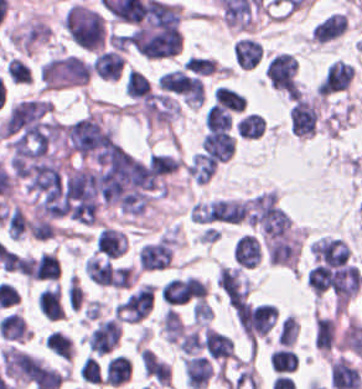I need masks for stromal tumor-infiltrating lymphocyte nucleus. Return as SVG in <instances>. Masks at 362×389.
<instances>
[{
	"label": "stromal tumor-infiltrating lymphocyte nucleus",
	"mask_w": 362,
	"mask_h": 389,
	"mask_svg": "<svg viewBox=\"0 0 362 389\" xmlns=\"http://www.w3.org/2000/svg\"><path fill=\"white\" fill-rule=\"evenodd\" d=\"M218 160L203 151H196L185 165V173L196 183L205 184L216 170Z\"/></svg>",
	"instance_id": "20"
},
{
	"label": "stromal tumor-infiltrating lymphocyte nucleus",
	"mask_w": 362,
	"mask_h": 389,
	"mask_svg": "<svg viewBox=\"0 0 362 389\" xmlns=\"http://www.w3.org/2000/svg\"><path fill=\"white\" fill-rule=\"evenodd\" d=\"M153 302V286L148 282L140 284L117 303V319L137 323L148 315Z\"/></svg>",
	"instance_id": "7"
},
{
	"label": "stromal tumor-infiltrating lymphocyte nucleus",
	"mask_w": 362,
	"mask_h": 389,
	"mask_svg": "<svg viewBox=\"0 0 362 389\" xmlns=\"http://www.w3.org/2000/svg\"><path fill=\"white\" fill-rule=\"evenodd\" d=\"M129 372L130 360L122 354H114L108 359L103 376L106 382L119 385L126 381Z\"/></svg>",
	"instance_id": "27"
},
{
	"label": "stromal tumor-infiltrating lymphocyte nucleus",
	"mask_w": 362,
	"mask_h": 389,
	"mask_svg": "<svg viewBox=\"0 0 362 389\" xmlns=\"http://www.w3.org/2000/svg\"><path fill=\"white\" fill-rule=\"evenodd\" d=\"M268 263L294 266L300 253L298 237L271 240L266 245Z\"/></svg>",
	"instance_id": "16"
},
{
	"label": "stromal tumor-infiltrating lymphocyte nucleus",
	"mask_w": 362,
	"mask_h": 389,
	"mask_svg": "<svg viewBox=\"0 0 362 389\" xmlns=\"http://www.w3.org/2000/svg\"><path fill=\"white\" fill-rule=\"evenodd\" d=\"M92 65L75 55L57 56L42 63L39 76L45 87L83 85Z\"/></svg>",
	"instance_id": "2"
},
{
	"label": "stromal tumor-infiltrating lymphocyte nucleus",
	"mask_w": 362,
	"mask_h": 389,
	"mask_svg": "<svg viewBox=\"0 0 362 389\" xmlns=\"http://www.w3.org/2000/svg\"><path fill=\"white\" fill-rule=\"evenodd\" d=\"M160 325L164 340L168 342H175L184 331L175 310L169 306L161 316Z\"/></svg>",
	"instance_id": "35"
},
{
	"label": "stromal tumor-infiltrating lymphocyte nucleus",
	"mask_w": 362,
	"mask_h": 389,
	"mask_svg": "<svg viewBox=\"0 0 362 389\" xmlns=\"http://www.w3.org/2000/svg\"><path fill=\"white\" fill-rule=\"evenodd\" d=\"M174 232H166L140 247L136 263L140 272H160L171 265L175 249Z\"/></svg>",
	"instance_id": "3"
},
{
	"label": "stromal tumor-infiltrating lymphocyte nucleus",
	"mask_w": 362,
	"mask_h": 389,
	"mask_svg": "<svg viewBox=\"0 0 362 389\" xmlns=\"http://www.w3.org/2000/svg\"><path fill=\"white\" fill-rule=\"evenodd\" d=\"M330 267L322 264L315 265L305 277V284L314 295L321 296L329 289Z\"/></svg>",
	"instance_id": "29"
},
{
	"label": "stromal tumor-infiltrating lymphocyte nucleus",
	"mask_w": 362,
	"mask_h": 389,
	"mask_svg": "<svg viewBox=\"0 0 362 389\" xmlns=\"http://www.w3.org/2000/svg\"><path fill=\"white\" fill-rule=\"evenodd\" d=\"M123 89L124 93L132 98H145L150 94V88L145 77L137 70H128Z\"/></svg>",
	"instance_id": "34"
},
{
	"label": "stromal tumor-infiltrating lymphocyte nucleus",
	"mask_w": 362,
	"mask_h": 389,
	"mask_svg": "<svg viewBox=\"0 0 362 389\" xmlns=\"http://www.w3.org/2000/svg\"><path fill=\"white\" fill-rule=\"evenodd\" d=\"M0 361L6 374L20 382H30L41 369L37 356L9 345L2 348Z\"/></svg>",
	"instance_id": "5"
},
{
	"label": "stromal tumor-infiltrating lymphocyte nucleus",
	"mask_w": 362,
	"mask_h": 389,
	"mask_svg": "<svg viewBox=\"0 0 362 389\" xmlns=\"http://www.w3.org/2000/svg\"><path fill=\"white\" fill-rule=\"evenodd\" d=\"M264 76L279 92L288 97L298 94L295 61L290 54L278 53L266 66Z\"/></svg>",
	"instance_id": "6"
},
{
	"label": "stromal tumor-infiltrating lymphocyte nucleus",
	"mask_w": 362,
	"mask_h": 389,
	"mask_svg": "<svg viewBox=\"0 0 362 389\" xmlns=\"http://www.w3.org/2000/svg\"><path fill=\"white\" fill-rule=\"evenodd\" d=\"M176 344L180 350L192 355L200 350L202 342L199 334L193 329L184 333Z\"/></svg>",
	"instance_id": "41"
},
{
	"label": "stromal tumor-infiltrating lymphocyte nucleus",
	"mask_w": 362,
	"mask_h": 389,
	"mask_svg": "<svg viewBox=\"0 0 362 389\" xmlns=\"http://www.w3.org/2000/svg\"><path fill=\"white\" fill-rule=\"evenodd\" d=\"M216 282L225 299L233 307L243 304L249 284L238 267H220Z\"/></svg>",
	"instance_id": "11"
},
{
	"label": "stromal tumor-infiltrating lymphocyte nucleus",
	"mask_w": 362,
	"mask_h": 389,
	"mask_svg": "<svg viewBox=\"0 0 362 389\" xmlns=\"http://www.w3.org/2000/svg\"><path fill=\"white\" fill-rule=\"evenodd\" d=\"M246 211V200L211 199L193 204L196 222H237Z\"/></svg>",
	"instance_id": "4"
},
{
	"label": "stromal tumor-infiltrating lymphocyte nucleus",
	"mask_w": 362,
	"mask_h": 389,
	"mask_svg": "<svg viewBox=\"0 0 362 389\" xmlns=\"http://www.w3.org/2000/svg\"><path fill=\"white\" fill-rule=\"evenodd\" d=\"M334 320L316 316L314 320V342L322 350H328L334 342Z\"/></svg>",
	"instance_id": "30"
},
{
	"label": "stromal tumor-infiltrating lymphocyte nucleus",
	"mask_w": 362,
	"mask_h": 389,
	"mask_svg": "<svg viewBox=\"0 0 362 389\" xmlns=\"http://www.w3.org/2000/svg\"><path fill=\"white\" fill-rule=\"evenodd\" d=\"M186 385L202 389L209 381L213 370L206 356H186L183 359Z\"/></svg>",
	"instance_id": "17"
},
{
	"label": "stromal tumor-infiltrating lymphocyte nucleus",
	"mask_w": 362,
	"mask_h": 389,
	"mask_svg": "<svg viewBox=\"0 0 362 389\" xmlns=\"http://www.w3.org/2000/svg\"><path fill=\"white\" fill-rule=\"evenodd\" d=\"M118 338V322L110 317L101 319L87 336L88 350L104 355L115 346Z\"/></svg>",
	"instance_id": "14"
},
{
	"label": "stromal tumor-infiltrating lymphocyte nucleus",
	"mask_w": 362,
	"mask_h": 389,
	"mask_svg": "<svg viewBox=\"0 0 362 389\" xmlns=\"http://www.w3.org/2000/svg\"><path fill=\"white\" fill-rule=\"evenodd\" d=\"M200 145L209 156L219 161L228 160L234 151V139L226 128L207 131Z\"/></svg>",
	"instance_id": "15"
},
{
	"label": "stromal tumor-infiltrating lymphocyte nucleus",
	"mask_w": 362,
	"mask_h": 389,
	"mask_svg": "<svg viewBox=\"0 0 362 389\" xmlns=\"http://www.w3.org/2000/svg\"><path fill=\"white\" fill-rule=\"evenodd\" d=\"M139 362L144 376L155 382L170 383V369L148 349H140Z\"/></svg>",
	"instance_id": "25"
},
{
	"label": "stromal tumor-infiltrating lymphocyte nucleus",
	"mask_w": 362,
	"mask_h": 389,
	"mask_svg": "<svg viewBox=\"0 0 362 389\" xmlns=\"http://www.w3.org/2000/svg\"><path fill=\"white\" fill-rule=\"evenodd\" d=\"M262 55V44L250 37H244L233 46V59L240 67L253 68Z\"/></svg>",
	"instance_id": "22"
},
{
	"label": "stromal tumor-infiltrating lymphocyte nucleus",
	"mask_w": 362,
	"mask_h": 389,
	"mask_svg": "<svg viewBox=\"0 0 362 389\" xmlns=\"http://www.w3.org/2000/svg\"><path fill=\"white\" fill-rule=\"evenodd\" d=\"M83 270L89 280L96 285L104 287L112 279L109 260L90 256L83 263Z\"/></svg>",
	"instance_id": "26"
},
{
	"label": "stromal tumor-infiltrating lymphocyte nucleus",
	"mask_w": 362,
	"mask_h": 389,
	"mask_svg": "<svg viewBox=\"0 0 362 389\" xmlns=\"http://www.w3.org/2000/svg\"><path fill=\"white\" fill-rule=\"evenodd\" d=\"M207 129H229L232 119L227 110L217 106H210L204 117Z\"/></svg>",
	"instance_id": "37"
},
{
	"label": "stromal tumor-infiltrating lymphocyte nucleus",
	"mask_w": 362,
	"mask_h": 389,
	"mask_svg": "<svg viewBox=\"0 0 362 389\" xmlns=\"http://www.w3.org/2000/svg\"><path fill=\"white\" fill-rule=\"evenodd\" d=\"M160 297L169 305H176L205 297L206 286L194 276L168 279L159 289Z\"/></svg>",
	"instance_id": "9"
},
{
	"label": "stromal tumor-infiltrating lymphocyte nucleus",
	"mask_w": 362,
	"mask_h": 389,
	"mask_svg": "<svg viewBox=\"0 0 362 389\" xmlns=\"http://www.w3.org/2000/svg\"><path fill=\"white\" fill-rule=\"evenodd\" d=\"M296 336L295 320L288 314L281 322L277 333L278 344L290 345Z\"/></svg>",
	"instance_id": "42"
},
{
	"label": "stromal tumor-infiltrating lymphocyte nucleus",
	"mask_w": 362,
	"mask_h": 389,
	"mask_svg": "<svg viewBox=\"0 0 362 389\" xmlns=\"http://www.w3.org/2000/svg\"><path fill=\"white\" fill-rule=\"evenodd\" d=\"M309 251L318 263L329 267L344 264L350 250L341 237L322 236L312 242Z\"/></svg>",
	"instance_id": "12"
},
{
	"label": "stromal tumor-infiltrating lymphocyte nucleus",
	"mask_w": 362,
	"mask_h": 389,
	"mask_svg": "<svg viewBox=\"0 0 362 389\" xmlns=\"http://www.w3.org/2000/svg\"><path fill=\"white\" fill-rule=\"evenodd\" d=\"M202 341L211 357L216 359H227L234 356L231 337L221 332L205 327Z\"/></svg>",
	"instance_id": "21"
},
{
	"label": "stromal tumor-infiltrating lymphocyte nucleus",
	"mask_w": 362,
	"mask_h": 389,
	"mask_svg": "<svg viewBox=\"0 0 362 389\" xmlns=\"http://www.w3.org/2000/svg\"><path fill=\"white\" fill-rule=\"evenodd\" d=\"M233 256L243 267H254L261 258V246L256 236L243 234L238 240Z\"/></svg>",
	"instance_id": "23"
},
{
	"label": "stromal tumor-infiltrating lymphocyte nucleus",
	"mask_w": 362,
	"mask_h": 389,
	"mask_svg": "<svg viewBox=\"0 0 362 389\" xmlns=\"http://www.w3.org/2000/svg\"><path fill=\"white\" fill-rule=\"evenodd\" d=\"M124 58L113 49L97 51L92 59V72L105 80H117Z\"/></svg>",
	"instance_id": "18"
},
{
	"label": "stromal tumor-infiltrating lymphocyte nucleus",
	"mask_w": 362,
	"mask_h": 389,
	"mask_svg": "<svg viewBox=\"0 0 362 389\" xmlns=\"http://www.w3.org/2000/svg\"><path fill=\"white\" fill-rule=\"evenodd\" d=\"M214 102L232 112H241L246 106V101L242 93L234 91L226 86H219L215 90Z\"/></svg>",
	"instance_id": "33"
},
{
	"label": "stromal tumor-infiltrating lymphocyte nucleus",
	"mask_w": 362,
	"mask_h": 389,
	"mask_svg": "<svg viewBox=\"0 0 362 389\" xmlns=\"http://www.w3.org/2000/svg\"><path fill=\"white\" fill-rule=\"evenodd\" d=\"M38 310L51 319L65 316L58 283L43 288L38 294Z\"/></svg>",
	"instance_id": "24"
},
{
	"label": "stromal tumor-infiltrating lymphocyte nucleus",
	"mask_w": 362,
	"mask_h": 389,
	"mask_svg": "<svg viewBox=\"0 0 362 389\" xmlns=\"http://www.w3.org/2000/svg\"><path fill=\"white\" fill-rule=\"evenodd\" d=\"M83 299L81 286L76 277L70 276L66 286V302L67 307L78 309Z\"/></svg>",
	"instance_id": "40"
},
{
	"label": "stromal tumor-infiltrating lymphocyte nucleus",
	"mask_w": 362,
	"mask_h": 389,
	"mask_svg": "<svg viewBox=\"0 0 362 389\" xmlns=\"http://www.w3.org/2000/svg\"><path fill=\"white\" fill-rule=\"evenodd\" d=\"M289 132L295 137H310L318 121L316 102L298 97L288 111Z\"/></svg>",
	"instance_id": "10"
},
{
	"label": "stromal tumor-infiltrating lymphocyte nucleus",
	"mask_w": 362,
	"mask_h": 389,
	"mask_svg": "<svg viewBox=\"0 0 362 389\" xmlns=\"http://www.w3.org/2000/svg\"><path fill=\"white\" fill-rule=\"evenodd\" d=\"M44 346L62 360L70 361L72 357L71 341L60 330H52L45 337Z\"/></svg>",
	"instance_id": "31"
},
{
	"label": "stromal tumor-infiltrating lymphocyte nucleus",
	"mask_w": 362,
	"mask_h": 389,
	"mask_svg": "<svg viewBox=\"0 0 362 389\" xmlns=\"http://www.w3.org/2000/svg\"><path fill=\"white\" fill-rule=\"evenodd\" d=\"M16 268L21 275L32 279L34 275V261L30 257H16Z\"/></svg>",
	"instance_id": "44"
},
{
	"label": "stromal tumor-infiltrating lymphocyte nucleus",
	"mask_w": 362,
	"mask_h": 389,
	"mask_svg": "<svg viewBox=\"0 0 362 389\" xmlns=\"http://www.w3.org/2000/svg\"><path fill=\"white\" fill-rule=\"evenodd\" d=\"M78 377L88 382H102L103 377L97 359L90 356L83 358L79 368Z\"/></svg>",
	"instance_id": "38"
},
{
	"label": "stromal tumor-infiltrating lymphocyte nucleus",
	"mask_w": 362,
	"mask_h": 389,
	"mask_svg": "<svg viewBox=\"0 0 362 389\" xmlns=\"http://www.w3.org/2000/svg\"><path fill=\"white\" fill-rule=\"evenodd\" d=\"M181 66L194 75H210L217 68L215 59L197 55L187 57Z\"/></svg>",
	"instance_id": "36"
},
{
	"label": "stromal tumor-infiltrating lymphocyte nucleus",
	"mask_w": 362,
	"mask_h": 389,
	"mask_svg": "<svg viewBox=\"0 0 362 389\" xmlns=\"http://www.w3.org/2000/svg\"><path fill=\"white\" fill-rule=\"evenodd\" d=\"M268 361L273 371L290 372L298 364V356L292 348L279 346L269 353Z\"/></svg>",
	"instance_id": "28"
},
{
	"label": "stromal tumor-infiltrating lymphocyte nucleus",
	"mask_w": 362,
	"mask_h": 389,
	"mask_svg": "<svg viewBox=\"0 0 362 389\" xmlns=\"http://www.w3.org/2000/svg\"><path fill=\"white\" fill-rule=\"evenodd\" d=\"M95 248L105 257L117 258L127 248V240L123 232L102 227L96 235Z\"/></svg>",
	"instance_id": "19"
},
{
	"label": "stromal tumor-infiltrating lymphocyte nucleus",
	"mask_w": 362,
	"mask_h": 389,
	"mask_svg": "<svg viewBox=\"0 0 362 389\" xmlns=\"http://www.w3.org/2000/svg\"><path fill=\"white\" fill-rule=\"evenodd\" d=\"M34 277L57 280L60 277L58 262L51 252L40 254L33 265Z\"/></svg>",
	"instance_id": "32"
},
{
	"label": "stromal tumor-infiltrating lymphocyte nucleus",
	"mask_w": 362,
	"mask_h": 389,
	"mask_svg": "<svg viewBox=\"0 0 362 389\" xmlns=\"http://www.w3.org/2000/svg\"><path fill=\"white\" fill-rule=\"evenodd\" d=\"M133 277L130 265L112 268L109 284L113 288H128Z\"/></svg>",
	"instance_id": "39"
},
{
	"label": "stromal tumor-infiltrating lymphocyte nucleus",
	"mask_w": 362,
	"mask_h": 389,
	"mask_svg": "<svg viewBox=\"0 0 362 389\" xmlns=\"http://www.w3.org/2000/svg\"><path fill=\"white\" fill-rule=\"evenodd\" d=\"M354 67L346 61L334 60L318 82V92L330 95L344 91L350 84Z\"/></svg>",
	"instance_id": "13"
},
{
	"label": "stromal tumor-infiltrating lymphocyte nucleus",
	"mask_w": 362,
	"mask_h": 389,
	"mask_svg": "<svg viewBox=\"0 0 362 389\" xmlns=\"http://www.w3.org/2000/svg\"><path fill=\"white\" fill-rule=\"evenodd\" d=\"M123 37L144 56L175 54L181 47L179 5L148 0Z\"/></svg>",
	"instance_id": "1"
},
{
	"label": "stromal tumor-infiltrating lymphocyte nucleus",
	"mask_w": 362,
	"mask_h": 389,
	"mask_svg": "<svg viewBox=\"0 0 362 389\" xmlns=\"http://www.w3.org/2000/svg\"><path fill=\"white\" fill-rule=\"evenodd\" d=\"M329 285L336 305H346L362 287L358 268L351 265L334 267L330 271Z\"/></svg>",
	"instance_id": "8"
},
{
	"label": "stromal tumor-infiltrating lymphocyte nucleus",
	"mask_w": 362,
	"mask_h": 389,
	"mask_svg": "<svg viewBox=\"0 0 362 389\" xmlns=\"http://www.w3.org/2000/svg\"><path fill=\"white\" fill-rule=\"evenodd\" d=\"M212 315V308L208 304L205 298H198L194 308L193 317L194 320L199 323H208Z\"/></svg>",
	"instance_id": "43"
}]
</instances>
